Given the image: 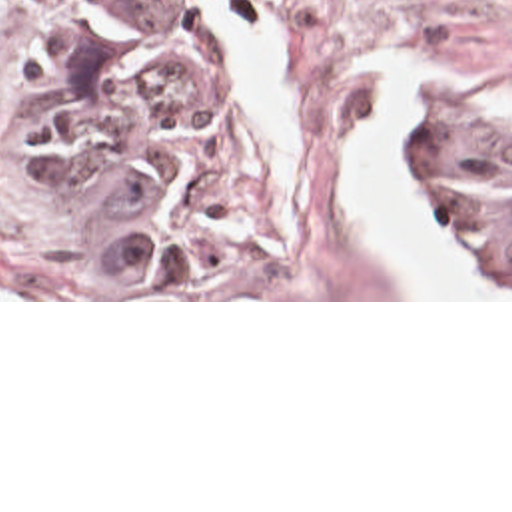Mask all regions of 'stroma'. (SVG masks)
<instances>
[{
    "mask_svg": "<svg viewBox=\"0 0 512 512\" xmlns=\"http://www.w3.org/2000/svg\"><path fill=\"white\" fill-rule=\"evenodd\" d=\"M69 0H0V302H512L455 238L447 214L403 172L409 198L491 282L493 298H397L339 192L351 132L373 118L367 62H421L473 78L512 102V0H191L243 64L271 90L293 132V246L251 298H123L41 204L21 192L3 160L9 102L33 70L41 42ZM271 26L285 54V96L249 60L211 3ZM417 92L437 98L481 132L512 142V122L469 98L413 86L397 102V158Z\"/></svg>",
    "mask_w": 512,
    "mask_h": 512,
    "instance_id": "stroma-1",
    "label": "stroma"
}]
</instances>
